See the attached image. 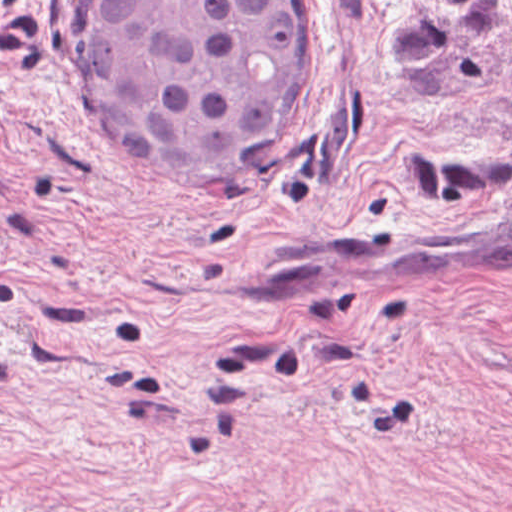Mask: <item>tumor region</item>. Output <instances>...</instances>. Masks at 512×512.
I'll return each instance as SVG.
<instances>
[{"instance_id": "e687c5a6", "label": "tumor region", "mask_w": 512, "mask_h": 512, "mask_svg": "<svg viewBox=\"0 0 512 512\" xmlns=\"http://www.w3.org/2000/svg\"><path fill=\"white\" fill-rule=\"evenodd\" d=\"M100 115L135 153L203 176H268L321 76L313 0H99Z\"/></svg>"}]
</instances>
